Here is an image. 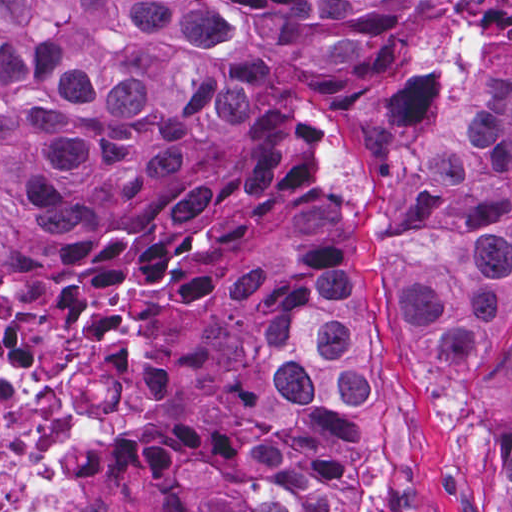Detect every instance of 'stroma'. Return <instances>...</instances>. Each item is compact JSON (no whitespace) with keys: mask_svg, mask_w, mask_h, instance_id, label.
Wrapping results in <instances>:
<instances>
[{"mask_svg":"<svg viewBox=\"0 0 512 512\" xmlns=\"http://www.w3.org/2000/svg\"><path fill=\"white\" fill-rule=\"evenodd\" d=\"M414 0L367 13L357 57L268 74L267 96L237 124L202 102L179 107L183 172L125 199L80 197L85 241L19 224L6 237L0 297L35 327L86 324L111 302L129 308L144 338L177 350L179 391L152 417L80 422L8 484L6 512H80L77 443L137 436L93 512H245L233 469L248 455L292 443L300 420L279 413L267 352L285 287L301 273L368 284L375 305L378 396L362 408L360 454L329 481L335 512H473L461 486L464 424L447 386L408 345L398 287L406 245L440 227L428 214L431 154L512 65V0H419L403 62L320 137L313 185L248 249L264 291L248 307H198L163 322L138 296L107 283L60 298L75 274L101 266L133 233L182 216L231 167L257 159L279 110L328 95L384 66Z\"/></svg>","mask_w":512,"mask_h":512,"instance_id":"35a3bbf8","label":"stroma"}]
</instances>
